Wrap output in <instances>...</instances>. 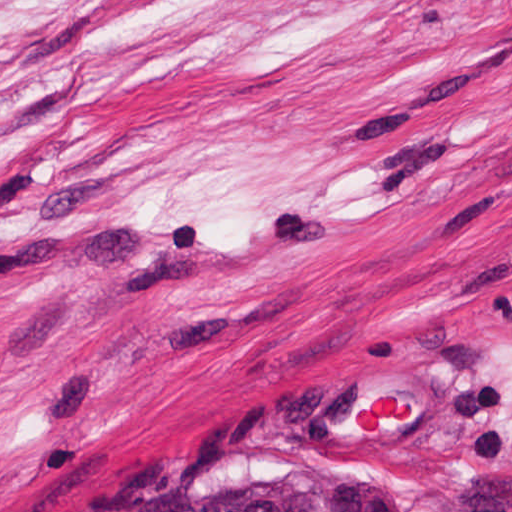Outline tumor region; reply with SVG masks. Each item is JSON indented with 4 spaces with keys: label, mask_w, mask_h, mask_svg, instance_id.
<instances>
[{
    "label": "tumor region",
    "mask_w": 512,
    "mask_h": 512,
    "mask_svg": "<svg viewBox=\"0 0 512 512\" xmlns=\"http://www.w3.org/2000/svg\"><path fill=\"white\" fill-rule=\"evenodd\" d=\"M120 512H405L391 488L340 463H251L207 472Z\"/></svg>",
    "instance_id": "obj_1"
}]
</instances>
